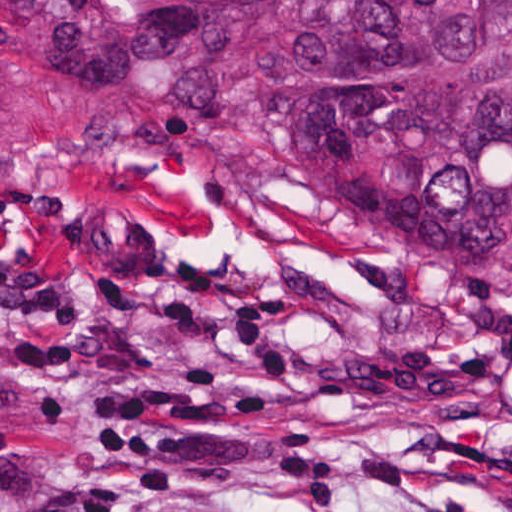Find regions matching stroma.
Returning <instances> with one entry per match:
<instances>
[{"label": "stroma", "instance_id": "35a3bbf8", "mask_svg": "<svg viewBox=\"0 0 512 512\" xmlns=\"http://www.w3.org/2000/svg\"><path fill=\"white\" fill-rule=\"evenodd\" d=\"M0 223L101 307L0 302V512H512V320L2 112Z\"/></svg>", "mask_w": 512, "mask_h": 512}]
</instances>
